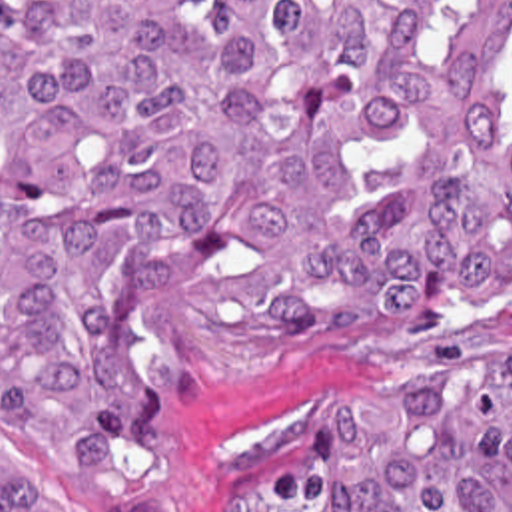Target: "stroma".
Returning a JSON list of instances; mask_svg holds the SVG:
<instances>
[{
  "mask_svg": "<svg viewBox=\"0 0 512 512\" xmlns=\"http://www.w3.org/2000/svg\"><path fill=\"white\" fill-rule=\"evenodd\" d=\"M512 352V280L411 326L289 352L229 394L181 378L173 469L157 512H199L245 481L289 420L377 386L449 380Z\"/></svg>",
  "mask_w": 512,
  "mask_h": 512,
  "instance_id": "stroma-1",
  "label": "stroma"
}]
</instances>
